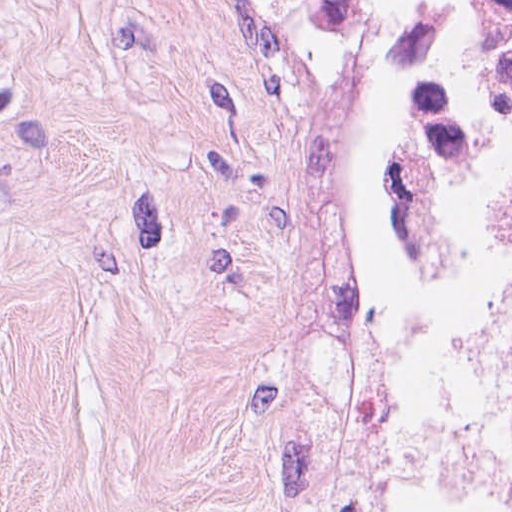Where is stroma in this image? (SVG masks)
<instances>
[{
    "instance_id": "stroma-1",
    "label": "stroma",
    "mask_w": 512,
    "mask_h": 512,
    "mask_svg": "<svg viewBox=\"0 0 512 512\" xmlns=\"http://www.w3.org/2000/svg\"><path fill=\"white\" fill-rule=\"evenodd\" d=\"M387 1L0 0V512H410L360 229Z\"/></svg>"
}]
</instances>
